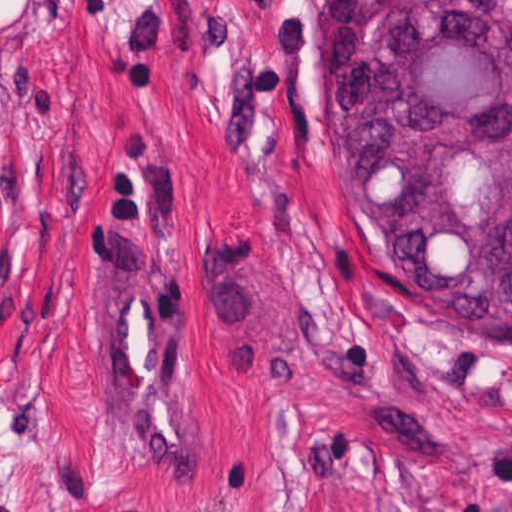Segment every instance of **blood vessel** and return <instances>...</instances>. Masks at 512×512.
Wrapping results in <instances>:
<instances>
[{"mask_svg":"<svg viewBox=\"0 0 512 512\" xmlns=\"http://www.w3.org/2000/svg\"><path fill=\"white\" fill-rule=\"evenodd\" d=\"M106 434L115 454L166 468L203 447V400L166 244L147 211L116 258L102 328Z\"/></svg>","mask_w":512,"mask_h":512,"instance_id":"obj_1","label":"blood vessel"}]
</instances>
